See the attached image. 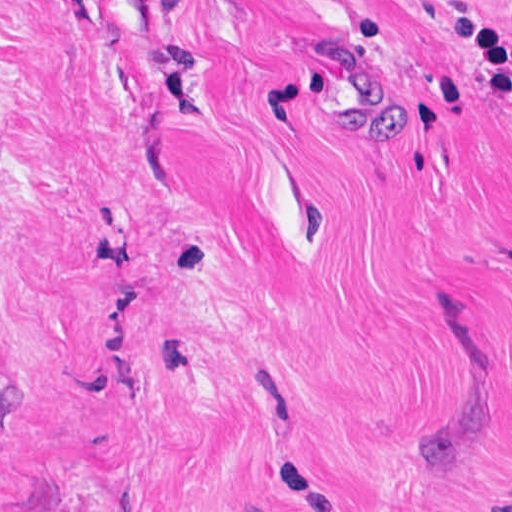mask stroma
Instances as JSON below:
<instances>
[{"label": "stroma", "mask_w": 512, "mask_h": 512, "mask_svg": "<svg viewBox=\"0 0 512 512\" xmlns=\"http://www.w3.org/2000/svg\"><path fill=\"white\" fill-rule=\"evenodd\" d=\"M0 512H512V0H0Z\"/></svg>", "instance_id": "stroma-1"}]
</instances>
